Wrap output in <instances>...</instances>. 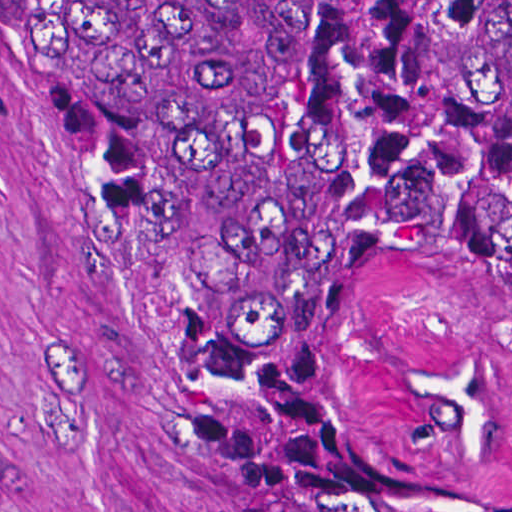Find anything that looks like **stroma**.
Here are the masks:
<instances>
[{
  "mask_svg": "<svg viewBox=\"0 0 512 512\" xmlns=\"http://www.w3.org/2000/svg\"><path fill=\"white\" fill-rule=\"evenodd\" d=\"M61 1L0 0V512H230V407L175 324Z\"/></svg>",
  "mask_w": 512,
  "mask_h": 512,
  "instance_id": "obj_1",
  "label": "stroma"
}]
</instances>
